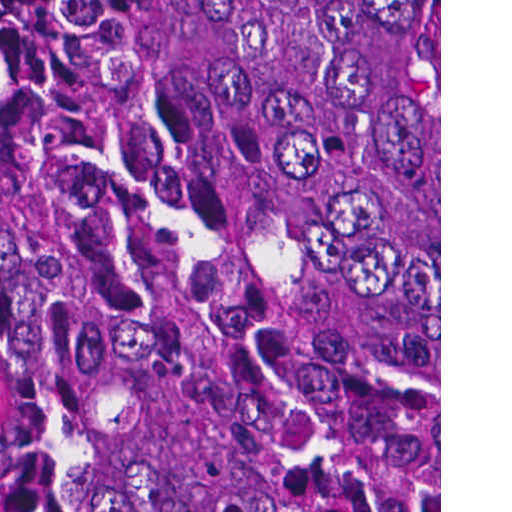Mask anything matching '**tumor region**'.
Wrapping results in <instances>:
<instances>
[{
	"label": "tumor region",
	"mask_w": 512,
	"mask_h": 512,
	"mask_svg": "<svg viewBox=\"0 0 512 512\" xmlns=\"http://www.w3.org/2000/svg\"><path fill=\"white\" fill-rule=\"evenodd\" d=\"M0 314L34 512H439V0H0Z\"/></svg>",
	"instance_id": "tumor-region-1"
}]
</instances>
